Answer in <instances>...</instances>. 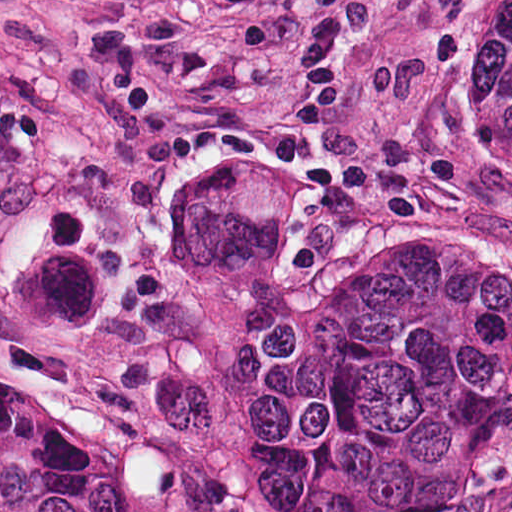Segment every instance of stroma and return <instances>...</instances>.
I'll return each instance as SVG.
<instances>
[{
  "mask_svg": "<svg viewBox=\"0 0 512 512\" xmlns=\"http://www.w3.org/2000/svg\"><path fill=\"white\" fill-rule=\"evenodd\" d=\"M428 250L512 324V104L191 0L25 512H512V362L408 497L249 490L321 277Z\"/></svg>",
  "mask_w": 512,
  "mask_h": 512,
  "instance_id": "stroma-1",
  "label": "stroma"
}]
</instances>
